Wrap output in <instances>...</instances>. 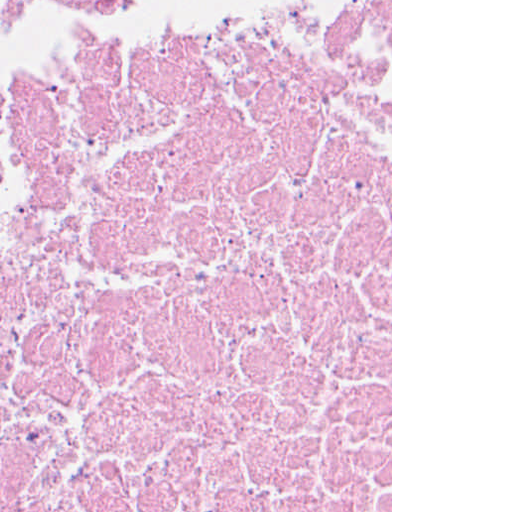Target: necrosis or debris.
<instances>
[{"mask_svg":"<svg viewBox=\"0 0 512 512\" xmlns=\"http://www.w3.org/2000/svg\"><path fill=\"white\" fill-rule=\"evenodd\" d=\"M153 0H0V102ZM0 512H391V0H227L0 129Z\"/></svg>","mask_w":512,"mask_h":512,"instance_id":"necrosis-or-debris-1","label":"necrosis or debris"}]
</instances>
